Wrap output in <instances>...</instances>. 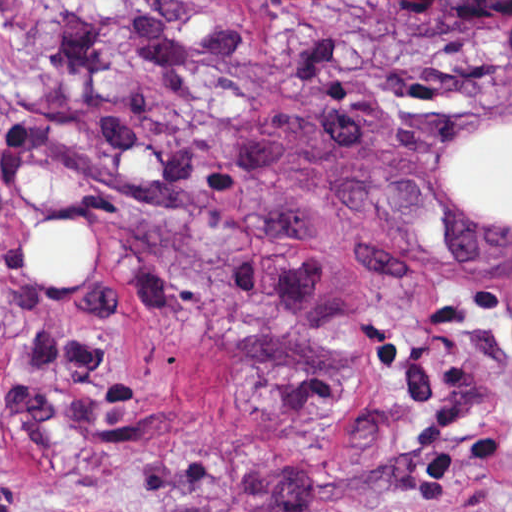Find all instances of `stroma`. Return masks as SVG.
I'll use <instances>...</instances> for the list:
<instances>
[{
  "instance_id": "stroma-1",
  "label": "stroma",
  "mask_w": 512,
  "mask_h": 512,
  "mask_svg": "<svg viewBox=\"0 0 512 512\" xmlns=\"http://www.w3.org/2000/svg\"><path fill=\"white\" fill-rule=\"evenodd\" d=\"M509 121L512 22L0 0V512H512V226L441 178ZM63 216L90 293L14 266Z\"/></svg>"
}]
</instances>
